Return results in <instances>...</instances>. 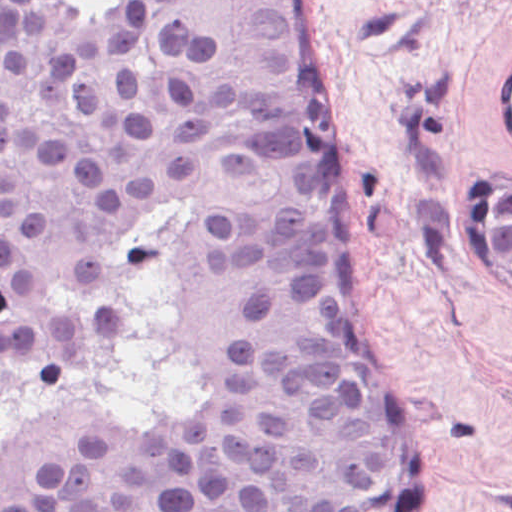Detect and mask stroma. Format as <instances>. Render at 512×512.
Wrapping results in <instances>:
<instances>
[{"instance_id": "35a3bbf8", "label": "stroma", "mask_w": 512, "mask_h": 512, "mask_svg": "<svg viewBox=\"0 0 512 512\" xmlns=\"http://www.w3.org/2000/svg\"><path fill=\"white\" fill-rule=\"evenodd\" d=\"M336 201L389 412L431 512H508L512 292L485 189L512 183V0H312Z\"/></svg>"}]
</instances>
